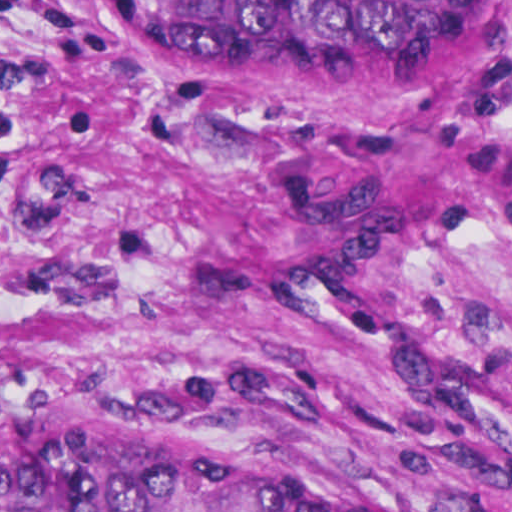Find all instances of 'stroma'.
Instances as JSON below:
<instances>
[{
    "label": "stroma",
    "mask_w": 512,
    "mask_h": 512,
    "mask_svg": "<svg viewBox=\"0 0 512 512\" xmlns=\"http://www.w3.org/2000/svg\"><path fill=\"white\" fill-rule=\"evenodd\" d=\"M158 0L0 17V386L368 512H512V0L207 64Z\"/></svg>",
    "instance_id": "stroma-1"
}]
</instances>
